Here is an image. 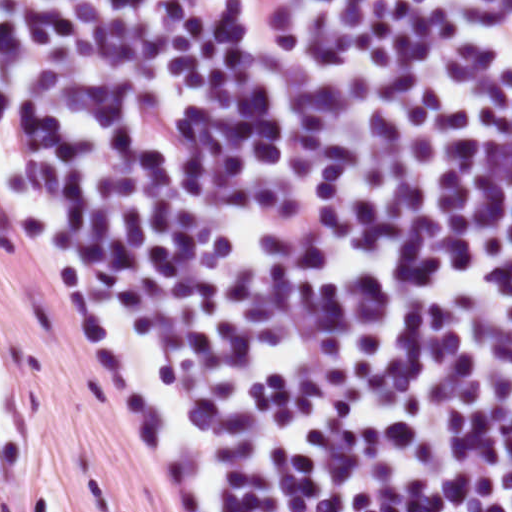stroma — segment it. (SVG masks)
<instances>
[{
    "mask_svg": "<svg viewBox=\"0 0 512 512\" xmlns=\"http://www.w3.org/2000/svg\"><path fill=\"white\" fill-rule=\"evenodd\" d=\"M0 373L27 411L54 512H172L114 394L98 330L15 248L1 201ZM25 506L0 455V512Z\"/></svg>",
    "mask_w": 512,
    "mask_h": 512,
    "instance_id": "stroma-1",
    "label": "stroma"
}]
</instances>
